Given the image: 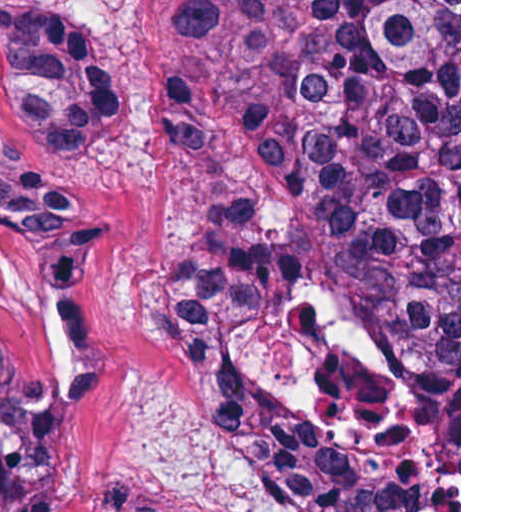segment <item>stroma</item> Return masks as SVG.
I'll use <instances>...</instances> for the list:
<instances>
[{"label": "stroma", "mask_w": 512, "mask_h": 512, "mask_svg": "<svg viewBox=\"0 0 512 512\" xmlns=\"http://www.w3.org/2000/svg\"><path fill=\"white\" fill-rule=\"evenodd\" d=\"M77 1L89 43L120 76L121 119L79 166L18 119L0 38V354L30 390L71 512H101L129 481L196 512H294L253 456L223 440L169 346L162 305L182 244L277 200L250 122L202 161L167 116L164 87L187 1H459V512H461V0Z\"/></svg>", "instance_id": "1"}]
</instances>
